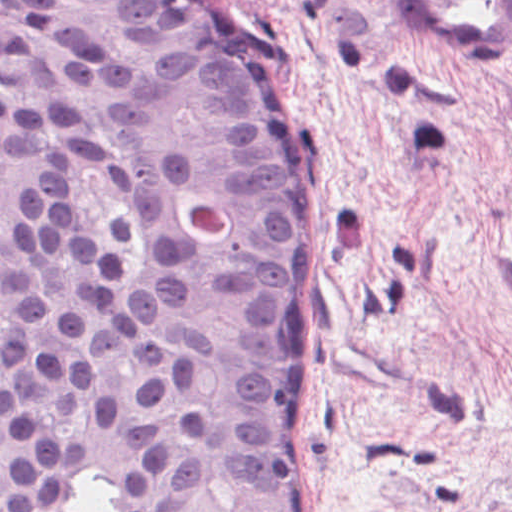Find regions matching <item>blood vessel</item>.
<instances>
[{
	"mask_svg": "<svg viewBox=\"0 0 512 512\" xmlns=\"http://www.w3.org/2000/svg\"><path fill=\"white\" fill-rule=\"evenodd\" d=\"M397 38L417 61L494 64L512 55V0H398ZM492 257L512 288V242Z\"/></svg>",
	"mask_w": 512,
	"mask_h": 512,
	"instance_id": "obj_1",
	"label": "blood vessel"
}]
</instances>
